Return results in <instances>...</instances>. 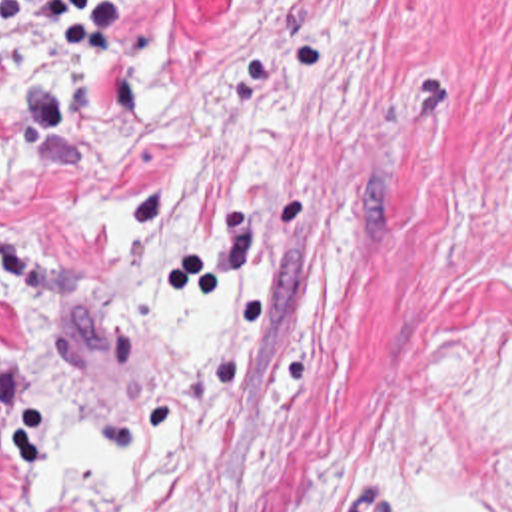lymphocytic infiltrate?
<instances>
[{
    "label": "lymphocytic infiltrate",
    "mask_w": 512,
    "mask_h": 512,
    "mask_svg": "<svg viewBox=\"0 0 512 512\" xmlns=\"http://www.w3.org/2000/svg\"><path fill=\"white\" fill-rule=\"evenodd\" d=\"M137 0H0V34L37 36L49 62L83 66L115 38Z\"/></svg>",
    "instance_id": "lymphocytic-infiltrate-1"
}]
</instances>
